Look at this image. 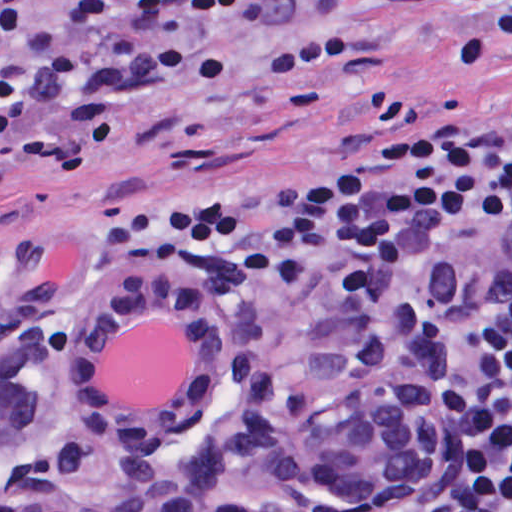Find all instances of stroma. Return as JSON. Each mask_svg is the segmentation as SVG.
I'll use <instances>...</instances> for the list:
<instances>
[{
    "instance_id": "stroma-1",
    "label": "stroma",
    "mask_w": 512,
    "mask_h": 512,
    "mask_svg": "<svg viewBox=\"0 0 512 512\" xmlns=\"http://www.w3.org/2000/svg\"><path fill=\"white\" fill-rule=\"evenodd\" d=\"M71 0H30L31 27L0 45V60ZM455 52L496 0H396ZM171 49L209 50L214 17L161 15L135 4L71 33L86 71L121 35ZM512 110V64H442L417 43L381 36L346 0H311L250 30L232 85L208 102L170 97L157 109L113 102L105 141L76 163L67 111L0 130L1 289H75L98 274H191L148 248L102 252L101 212L162 184L218 177L239 164L373 147ZM362 308V307H358Z\"/></svg>"
}]
</instances>
